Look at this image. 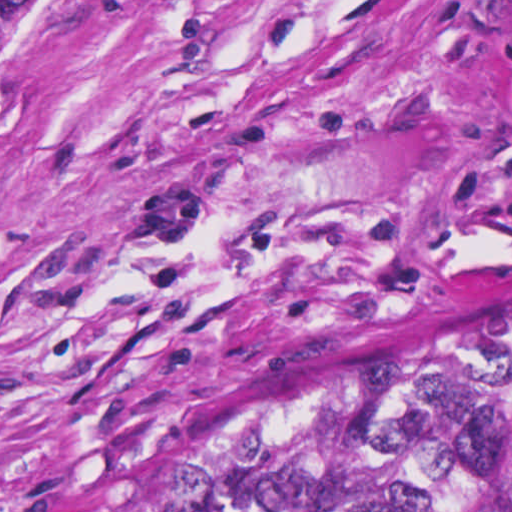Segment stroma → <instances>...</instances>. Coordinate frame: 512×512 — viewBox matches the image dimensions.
I'll return each mask as SVG.
<instances>
[{
  "label": "stroma",
  "mask_w": 512,
  "mask_h": 512,
  "mask_svg": "<svg viewBox=\"0 0 512 512\" xmlns=\"http://www.w3.org/2000/svg\"><path fill=\"white\" fill-rule=\"evenodd\" d=\"M511 264L512 0H99L0 122V512Z\"/></svg>",
  "instance_id": "1"
}]
</instances>
